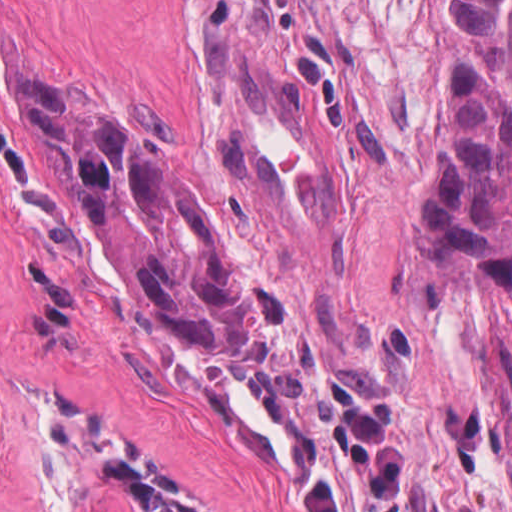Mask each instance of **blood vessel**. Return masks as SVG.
I'll list each match as a JSON object with an SVG mask.
<instances>
[{"label": "blood vessel", "mask_w": 512, "mask_h": 512, "mask_svg": "<svg viewBox=\"0 0 512 512\" xmlns=\"http://www.w3.org/2000/svg\"><path fill=\"white\" fill-rule=\"evenodd\" d=\"M213 113L233 179L260 230L279 241L335 231L344 155L311 78L271 54L211 41Z\"/></svg>", "instance_id": "obj_1"}]
</instances>
